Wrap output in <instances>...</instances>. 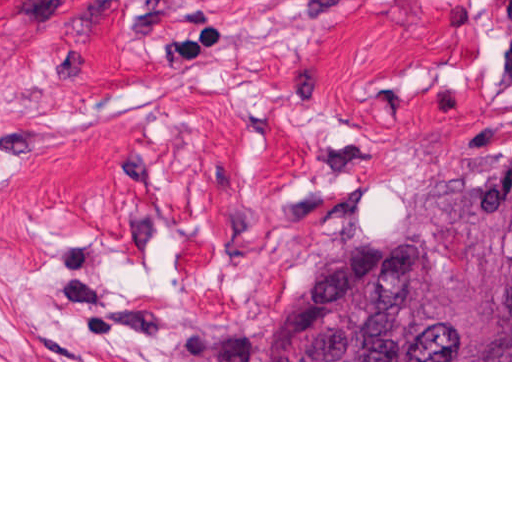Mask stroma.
Here are the masks:
<instances>
[{
	"label": "stroma",
	"mask_w": 512,
	"mask_h": 512,
	"mask_svg": "<svg viewBox=\"0 0 512 512\" xmlns=\"http://www.w3.org/2000/svg\"><path fill=\"white\" fill-rule=\"evenodd\" d=\"M512 160V0H0V362L258 360Z\"/></svg>",
	"instance_id": "obj_1"
}]
</instances>
